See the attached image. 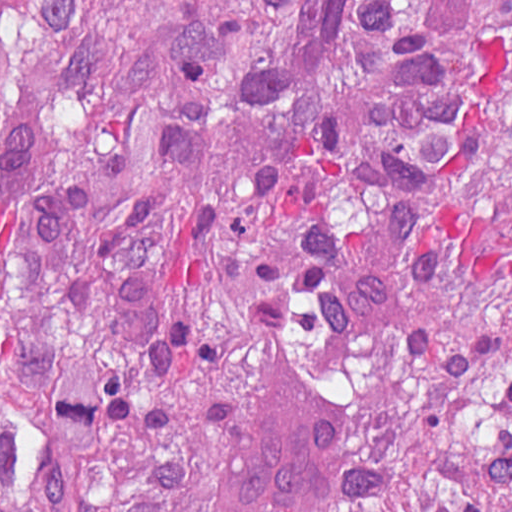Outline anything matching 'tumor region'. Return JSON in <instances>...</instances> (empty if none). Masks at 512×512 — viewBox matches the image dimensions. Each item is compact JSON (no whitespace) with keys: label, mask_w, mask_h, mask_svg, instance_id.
<instances>
[{"label":"tumor region","mask_w":512,"mask_h":512,"mask_svg":"<svg viewBox=\"0 0 512 512\" xmlns=\"http://www.w3.org/2000/svg\"><path fill=\"white\" fill-rule=\"evenodd\" d=\"M285 360L315 512H512V0H0V512H231Z\"/></svg>","instance_id":"e687c5a6"}]
</instances>
